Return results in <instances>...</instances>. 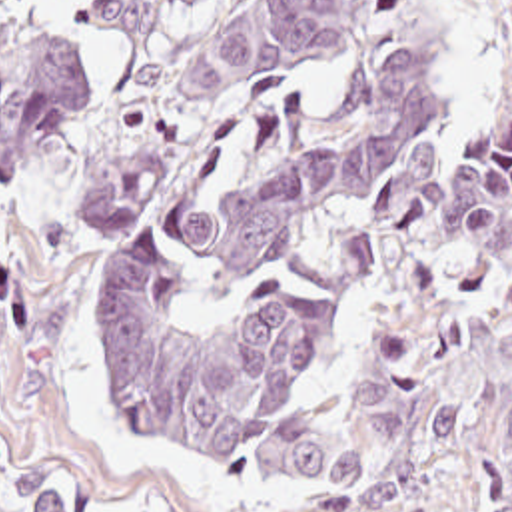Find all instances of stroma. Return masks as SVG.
Here are the masks:
<instances>
[{"mask_svg": "<svg viewBox=\"0 0 512 512\" xmlns=\"http://www.w3.org/2000/svg\"><path fill=\"white\" fill-rule=\"evenodd\" d=\"M93 0H11L0 32L67 36L95 88L47 158L0 180V512H29L21 456L123 512H486L480 416L508 390L498 336L444 294H424L360 230L314 210L259 262L183 292L173 322L203 334L269 284L318 288L334 302L328 346L289 406L344 412L380 340H408L436 372L464 386L444 452L388 495L346 507H275L257 491L247 448L231 460L173 454L113 396L95 344L107 274L133 252L191 230L275 180L322 142L344 112L340 70L285 76L239 106L169 186L109 236L75 242L81 172L107 126L157 68L211 28L235 0H205L157 36H109L87 24ZM440 62L434 134L450 156L512 112V0H428Z\"/></svg>", "mask_w": 512, "mask_h": 512, "instance_id": "35a3bbf8", "label": "stroma"}]
</instances>
